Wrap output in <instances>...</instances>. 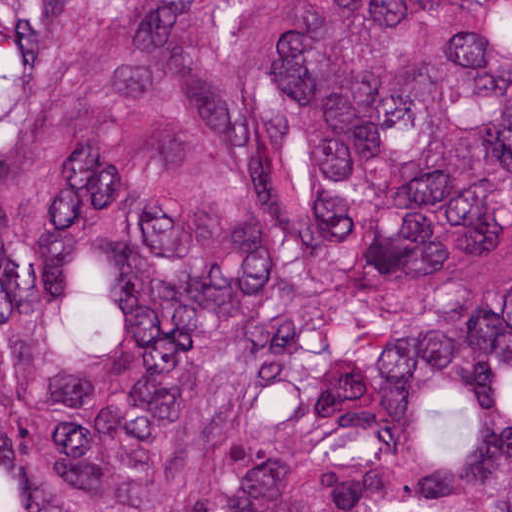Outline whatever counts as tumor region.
I'll return each mask as SVG.
<instances>
[{
    "mask_svg": "<svg viewBox=\"0 0 512 512\" xmlns=\"http://www.w3.org/2000/svg\"><path fill=\"white\" fill-rule=\"evenodd\" d=\"M0 512H512V0H0Z\"/></svg>",
    "mask_w": 512,
    "mask_h": 512,
    "instance_id": "tumor-region-1",
    "label": "tumor region"
}]
</instances>
